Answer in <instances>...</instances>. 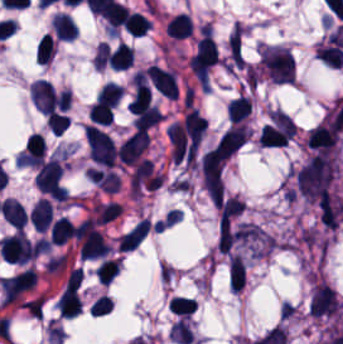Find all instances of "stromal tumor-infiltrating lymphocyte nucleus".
<instances>
[{
	"label": "stromal tumor-infiltrating lymphocyte nucleus",
	"mask_w": 343,
	"mask_h": 344,
	"mask_svg": "<svg viewBox=\"0 0 343 344\" xmlns=\"http://www.w3.org/2000/svg\"><path fill=\"white\" fill-rule=\"evenodd\" d=\"M151 229V220L141 218L135 225H133L124 235L118 245L119 250L132 249L138 245Z\"/></svg>",
	"instance_id": "4f13568d"
},
{
	"label": "stromal tumor-infiltrating lymphocyte nucleus",
	"mask_w": 343,
	"mask_h": 344,
	"mask_svg": "<svg viewBox=\"0 0 343 344\" xmlns=\"http://www.w3.org/2000/svg\"><path fill=\"white\" fill-rule=\"evenodd\" d=\"M56 308L66 317H74L81 313L82 305L75 286L68 284L62 291Z\"/></svg>",
	"instance_id": "abfb95fc"
},
{
	"label": "stromal tumor-infiltrating lymphocyte nucleus",
	"mask_w": 343,
	"mask_h": 344,
	"mask_svg": "<svg viewBox=\"0 0 343 344\" xmlns=\"http://www.w3.org/2000/svg\"><path fill=\"white\" fill-rule=\"evenodd\" d=\"M168 306L174 313L188 318L196 309L197 304L191 297L176 294L171 297Z\"/></svg>",
	"instance_id": "9e4306bb"
},
{
	"label": "stromal tumor-infiltrating lymphocyte nucleus",
	"mask_w": 343,
	"mask_h": 344,
	"mask_svg": "<svg viewBox=\"0 0 343 344\" xmlns=\"http://www.w3.org/2000/svg\"><path fill=\"white\" fill-rule=\"evenodd\" d=\"M146 74L157 92H159L163 96H168L176 99L177 83L175 74L152 63L150 64Z\"/></svg>",
	"instance_id": "52c7bb5b"
},
{
	"label": "stromal tumor-infiltrating lymphocyte nucleus",
	"mask_w": 343,
	"mask_h": 344,
	"mask_svg": "<svg viewBox=\"0 0 343 344\" xmlns=\"http://www.w3.org/2000/svg\"><path fill=\"white\" fill-rule=\"evenodd\" d=\"M97 280L103 284H109L118 273V259L103 258L95 268Z\"/></svg>",
	"instance_id": "42bb06b2"
},
{
	"label": "stromal tumor-infiltrating lymphocyte nucleus",
	"mask_w": 343,
	"mask_h": 344,
	"mask_svg": "<svg viewBox=\"0 0 343 344\" xmlns=\"http://www.w3.org/2000/svg\"><path fill=\"white\" fill-rule=\"evenodd\" d=\"M128 14V8L116 0H109L102 10V17L109 31L115 33L124 25Z\"/></svg>",
	"instance_id": "3290ff9b"
},
{
	"label": "stromal tumor-infiltrating lymphocyte nucleus",
	"mask_w": 343,
	"mask_h": 344,
	"mask_svg": "<svg viewBox=\"0 0 343 344\" xmlns=\"http://www.w3.org/2000/svg\"><path fill=\"white\" fill-rule=\"evenodd\" d=\"M252 101L245 95L234 96L227 104V116L230 122L238 123L248 119Z\"/></svg>",
	"instance_id": "2a367800"
},
{
	"label": "stromal tumor-infiltrating lymphocyte nucleus",
	"mask_w": 343,
	"mask_h": 344,
	"mask_svg": "<svg viewBox=\"0 0 343 344\" xmlns=\"http://www.w3.org/2000/svg\"><path fill=\"white\" fill-rule=\"evenodd\" d=\"M74 237L71 221L64 217L56 219L52 225L51 241L55 245H62Z\"/></svg>",
	"instance_id": "2761f720"
},
{
	"label": "stromal tumor-infiltrating lymphocyte nucleus",
	"mask_w": 343,
	"mask_h": 344,
	"mask_svg": "<svg viewBox=\"0 0 343 344\" xmlns=\"http://www.w3.org/2000/svg\"><path fill=\"white\" fill-rule=\"evenodd\" d=\"M70 118L58 111H51L46 115V122L52 134H61L68 127Z\"/></svg>",
	"instance_id": "cac63f63"
},
{
	"label": "stromal tumor-infiltrating lymphocyte nucleus",
	"mask_w": 343,
	"mask_h": 344,
	"mask_svg": "<svg viewBox=\"0 0 343 344\" xmlns=\"http://www.w3.org/2000/svg\"><path fill=\"white\" fill-rule=\"evenodd\" d=\"M151 24V20L140 15L137 12H129L127 14L126 29L131 35L139 36L144 33Z\"/></svg>",
	"instance_id": "04cf8593"
},
{
	"label": "stromal tumor-infiltrating lymphocyte nucleus",
	"mask_w": 343,
	"mask_h": 344,
	"mask_svg": "<svg viewBox=\"0 0 343 344\" xmlns=\"http://www.w3.org/2000/svg\"><path fill=\"white\" fill-rule=\"evenodd\" d=\"M89 308L93 314L98 316L110 311L111 302L109 298L102 293L101 295H99L97 298L94 299V301L91 303Z\"/></svg>",
	"instance_id": "7eef579d"
},
{
	"label": "stromal tumor-infiltrating lymphocyte nucleus",
	"mask_w": 343,
	"mask_h": 344,
	"mask_svg": "<svg viewBox=\"0 0 343 344\" xmlns=\"http://www.w3.org/2000/svg\"><path fill=\"white\" fill-rule=\"evenodd\" d=\"M51 24L56 37L71 40L77 35L75 21L71 15L56 13Z\"/></svg>",
	"instance_id": "4803ca6d"
},
{
	"label": "stromal tumor-infiltrating lymphocyte nucleus",
	"mask_w": 343,
	"mask_h": 344,
	"mask_svg": "<svg viewBox=\"0 0 343 344\" xmlns=\"http://www.w3.org/2000/svg\"><path fill=\"white\" fill-rule=\"evenodd\" d=\"M55 52V43L46 33L37 44L35 59L37 63H48Z\"/></svg>",
	"instance_id": "e9af9c67"
},
{
	"label": "stromal tumor-infiltrating lymphocyte nucleus",
	"mask_w": 343,
	"mask_h": 344,
	"mask_svg": "<svg viewBox=\"0 0 343 344\" xmlns=\"http://www.w3.org/2000/svg\"><path fill=\"white\" fill-rule=\"evenodd\" d=\"M229 284L238 292L245 285V264L239 254H232L229 261Z\"/></svg>",
	"instance_id": "4c9ddf68"
},
{
	"label": "stromal tumor-infiltrating lymphocyte nucleus",
	"mask_w": 343,
	"mask_h": 344,
	"mask_svg": "<svg viewBox=\"0 0 343 344\" xmlns=\"http://www.w3.org/2000/svg\"><path fill=\"white\" fill-rule=\"evenodd\" d=\"M259 64L272 82L293 83L294 57L286 48L263 44Z\"/></svg>",
	"instance_id": "bc302bb0"
},
{
	"label": "stromal tumor-infiltrating lymphocyte nucleus",
	"mask_w": 343,
	"mask_h": 344,
	"mask_svg": "<svg viewBox=\"0 0 343 344\" xmlns=\"http://www.w3.org/2000/svg\"><path fill=\"white\" fill-rule=\"evenodd\" d=\"M113 117L110 104L101 99H96L90 104L89 119L91 122L108 124Z\"/></svg>",
	"instance_id": "3c572f05"
},
{
	"label": "stromal tumor-infiltrating lymphocyte nucleus",
	"mask_w": 343,
	"mask_h": 344,
	"mask_svg": "<svg viewBox=\"0 0 343 344\" xmlns=\"http://www.w3.org/2000/svg\"><path fill=\"white\" fill-rule=\"evenodd\" d=\"M1 215L9 225L19 230L27 222V214L21 203L8 197L1 202Z\"/></svg>",
	"instance_id": "f3e2335f"
},
{
	"label": "stromal tumor-infiltrating lymphocyte nucleus",
	"mask_w": 343,
	"mask_h": 344,
	"mask_svg": "<svg viewBox=\"0 0 343 344\" xmlns=\"http://www.w3.org/2000/svg\"><path fill=\"white\" fill-rule=\"evenodd\" d=\"M166 34L170 37H190L192 31L191 20L186 13L174 15L165 27Z\"/></svg>",
	"instance_id": "4245b91a"
},
{
	"label": "stromal tumor-infiltrating lymphocyte nucleus",
	"mask_w": 343,
	"mask_h": 344,
	"mask_svg": "<svg viewBox=\"0 0 343 344\" xmlns=\"http://www.w3.org/2000/svg\"><path fill=\"white\" fill-rule=\"evenodd\" d=\"M170 336L171 340L183 344H188L193 337L188 322H186L182 318L175 322L170 332Z\"/></svg>",
	"instance_id": "2e467ee5"
},
{
	"label": "stromal tumor-infiltrating lymphocyte nucleus",
	"mask_w": 343,
	"mask_h": 344,
	"mask_svg": "<svg viewBox=\"0 0 343 344\" xmlns=\"http://www.w3.org/2000/svg\"><path fill=\"white\" fill-rule=\"evenodd\" d=\"M52 219L51 202L40 198L29 210L28 220L33 228L43 231Z\"/></svg>",
	"instance_id": "9ea309e8"
},
{
	"label": "stromal tumor-infiltrating lymphocyte nucleus",
	"mask_w": 343,
	"mask_h": 344,
	"mask_svg": "<svg viewBox=\"0 0 343 344\" xmlns=\"http://www.w3.org/2000/svg\"><path fill=\"white\" fill-rule=\"evenodd\" d=\"M122 89H123V85L115 81L108 80L103 85L98 97H100L101 99H103L104 101H106L107 103H109L110 105L114 107L119 102Z\"/></svg>",
	"instance_id": "782c7336"
}]
</instances>
